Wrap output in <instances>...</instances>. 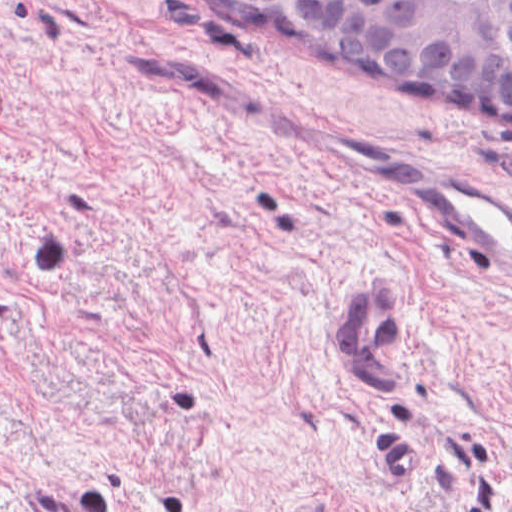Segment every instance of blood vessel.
I'll use <instances>...</instances> for the list:
<instances>
[{
  "label": "blood vessel",
  "mask_w": 512,
  "mask_h": 512,
  "mask_svg": "<svg viewBox=\"0 0 512 512\" xmlns=\"http://www.w3.org/2000/svg\"><path fill=\"white\" fill-rule=\"evenodd\" d=\"M393 191L497 283H512V197L431 165L385 167ZM395 274V273H394ZM373 275L348 289L339 335L361 385L389 399L398 379L390 349L403 326V281Z\"/></svg>",
  "instance_id": "blood-vessel-1"
}]
</instances>
